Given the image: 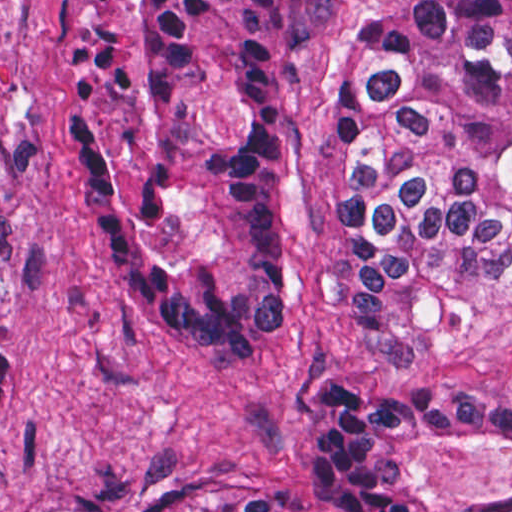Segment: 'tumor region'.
Wrapping results in <instances>:
<instances>
[{
  "label": "tumor region",
  "instance_id": "e687c5a6",
  "mask_svg": "<svg viewBox=\"0 0 512 512\" xmlns=\"http://www.w3.org/2000/svg\"><path fill=\"white\" fill-rule=\"evenodd\" d=\"M325 0H73L60 113L88 217L182 360L264 377L291 317L283 71ZM512 0H415L358 28L318 114L346 319L384 364L442 357L506 291ZM0 345V392L13 363ZM512 444L510 396L319 393L303 489L329 512H512L402 489L396 454ZM198 512H303L215 497Z\"/></svg>",
  "mask_w": 512,
  "mask_h": 512
}]
</instances>
